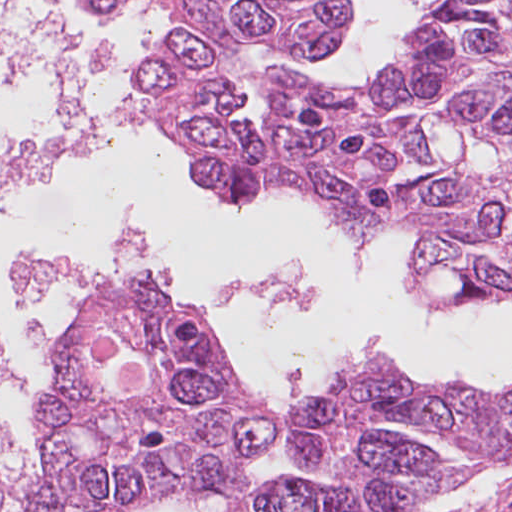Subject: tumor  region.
Here are the masks:
<instances>
[{"mask_svg": "<svg viewBox=\"0 0 512 512\" xmlns=\"http://www.w3.org/2000/svg\"><path fill=\"white\" fill-rule=\"evenodd\" d=\"M345 1L158 0L179 22L147 106L232 205L297 189L372 252L414 235L421 298L511 301L512 0L435 4L353 89L246 68L265 135L233 121L220 41L337 54ZM278 427L247 408L171 294L131 284L62 338L32 512H411L512 461V394L430 387L388 356Z\"/></svg>", "mask_w": 512, "mask_h": 512, "instance_id": "e687c5a6", "label": "tumor region"}]
</instances>
